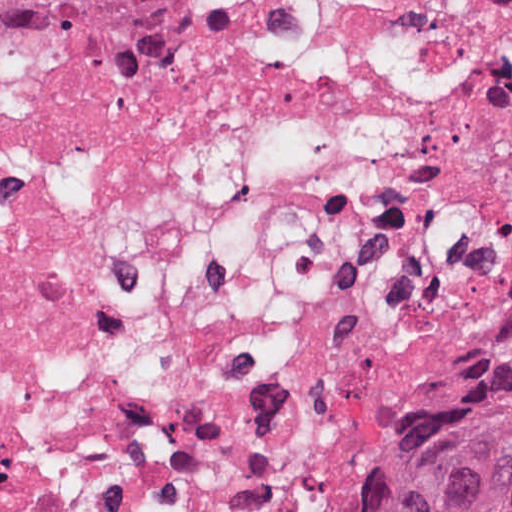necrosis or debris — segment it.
Here are the masks:
<instances>
[{
    "mask_svg": "<svg viewBox=\"0 0 512 512\" xmlns=\"http://www.w3.org/2000/svg\"><path fill=\"white\" fill-rule=\"evenodd\" d=\"M512 348V0H243L0 95V512H340Z\"/></svg>",
    "mask_w": 512,
    "mask_h": 512,
    "instance_id": "obj_1",
    "label": "necrosis or debris"
}]
</instances>
